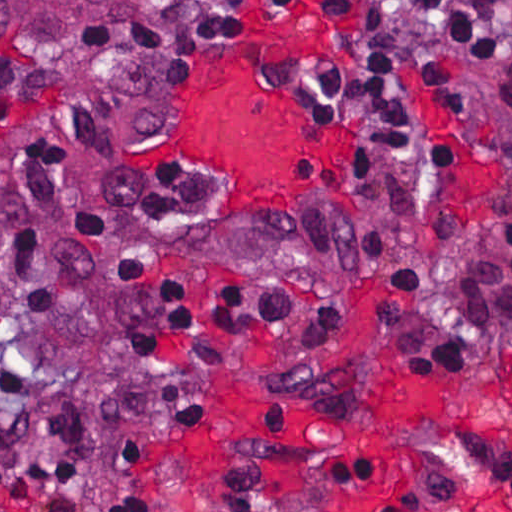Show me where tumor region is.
Instances as JSON below:
<instances>
[{"label": "tumor region", "instance_id": "e687c5a6", "mask_svg": "<svg viewBox=\"0 0 512 512\" xmlns=\"http://www.w3.org/2000/svg\"><path fill=\"white\" fill-rule=\"evenodd\" d=\"M171 1L0 0V49L57 66L98 69Z\"/></svg>", "mask_w": 512, "mask_h": 512}]
</instances>
